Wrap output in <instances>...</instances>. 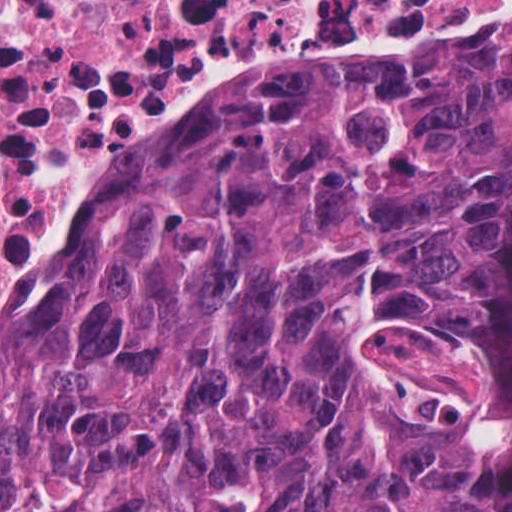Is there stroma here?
<instances>
[{
	"label": "stroma",
	"instance_id": "obj_1",
	"mask_svg": "<svg viewBox=\"0 0 512 512\" xmlns=\"http://www.w3.org/2000/svg\"><path fill=\"white\" fill-rule=\"evenodd\" d=\"M512 51V0L481 19L423 17L342 34L256 32L218 69L115 121L49 167L0 243V313L56 231L146 142L222 105ZM512 512V505L511 510Z\"/></svg>",
	"mask_w": 512,
	"mask_h": 512
}]
</instances>
